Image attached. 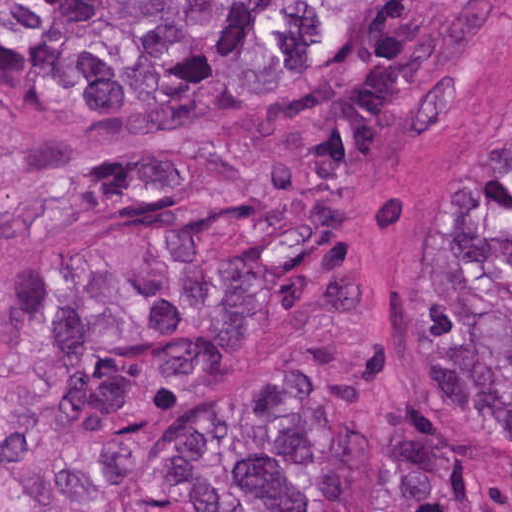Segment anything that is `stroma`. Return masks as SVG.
Returning <instances> with one entry per match:
<instances>
[{"instance_id": "35a3bbf8", "label": "stroma", "mask_w": 512, "mask_h": 512, "mask_svg": "<svg viewBox=\"0 0 512 512\" xmlns=\"http://www.w3.org/2000/svg\"><path fill=\"white\" fill-rule=\"evenodd\" d=\"M0 1H363V22L382 9L416 1H503L506 26L473 76L456 125L389 165L371 184V267L351 299L328 314H301L238 331L225 343L229 370L188 411L177 429L232 383L255 374L319 376L336 385L373 432H409L422 414L417 322L438 218L447 193L477 147L512 118V0H0ZM285 95L226 113L175 134L103 144L73 141L75 168L48 182L22 173L0 179V310L7 301L106 279L120 271L129 247L149 233L127 213L95 217L50 234L36 200L69 177L122 167L177 145L190 133H211L287 102ZM11 125L36 132L4 107ZM478 475V512H512V443L464 438ZM154 455L120 479H38L16 474L0 457V512H145L141 486Z\"/></svg>"}]
</instances>
